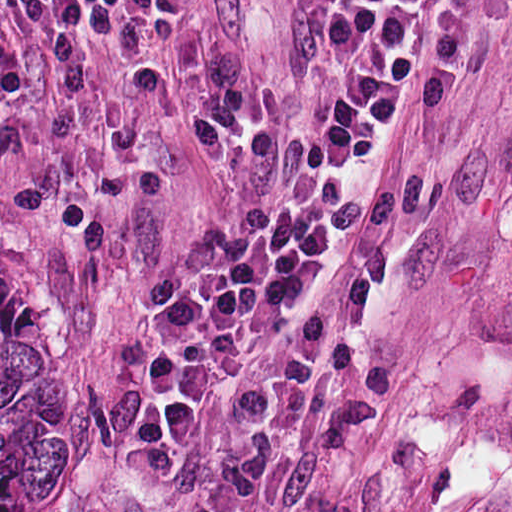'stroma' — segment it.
I'll return each instance as SVG.
<instances>
[{
  "mask_svg": "<svg viewBox=\"0 0 512 512\" xmlns=\"http://www.w3.org/2000/svg\"><path fill=\"white\" fill-rule=\"evenodd\" d=\"M320 5L45 37L0 0V241L63 355V512H427L512 253V0L437 1L317 274L253 327L327 304L324 365L197 420L175 478L123 455L180 242L314 184Z\"/></svg>",
  "mask_w": 512,
  "mask_h": 512,
  "instance_id": "stroma-1",
  "label": "stroma"
}]
</instances>
